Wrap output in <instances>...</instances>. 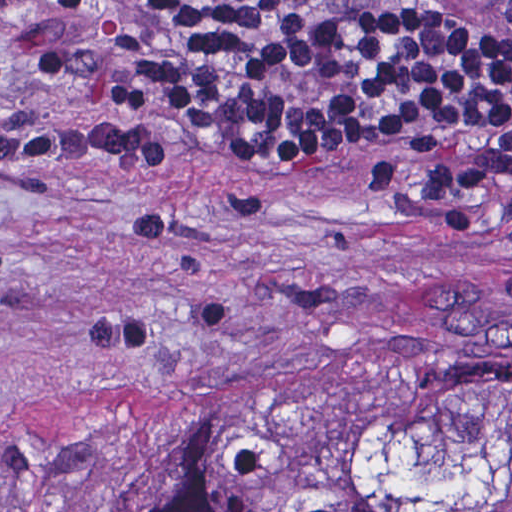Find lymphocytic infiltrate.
<instances>
[{"mask_svg": "<svg viewBox=\"0 0 512 512\" xmlns=\"http://www.w3.org/2000/svg\"><path fill=\"white\" fill-rule=\"evenodd\" d=\"M78 84L55 125L167 163V115L273 176L385 147L421 202L512 194V0H69L24 14Z\"/></svg>", "mask_w": 512, "mask_h": 512, "instance_id": "obj_1", "label": "lymphocytic infiltrate"}]
</instances>
